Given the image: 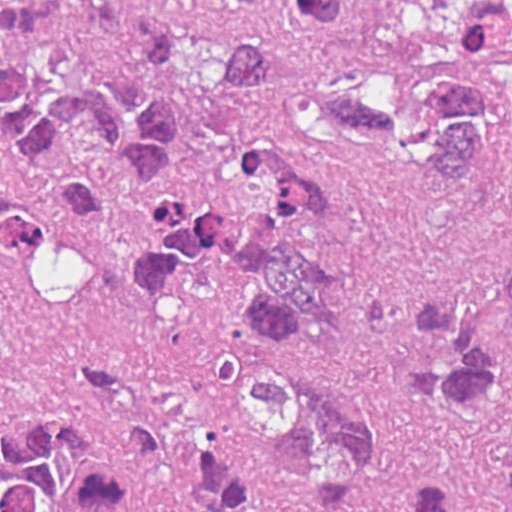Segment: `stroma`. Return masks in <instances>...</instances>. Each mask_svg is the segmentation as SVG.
Masks as SVG:
<instances>
[{
    "instance_id": "stroma-1",
    "label": "stroma",
    "mask_w": 512,
    "mask_h": 512,
    "mask_svg": "<svg viewBox=\"0 0 512 512\" xmlns=\"http://www.w3.org/2000/svg\"><path fill=\"white\" fill-rule=\"evenodd\" d=\"M191 19L239 25L274 49L258 111L262 129L302 142L345 170L353 189L345 364L386 419L382 476L357 509L403 512L418 473L446 448L438 426L401 384L395 359L415 304L434 286L488 259L501 222L404 163H363L313 130L301 88L323 76L364 80L357 46L296 25L285 0H149ZM482 0H355L367 29L387 41H435ZM109 206L98 222L63 208L40 176L0 143L43 207L55 236L84 249L95 300L74 312L41 298L29 272L41 250L0 258V444L74 424L69 443L119 470L100 512H201L187 501V461L207 424L223 343L252 313L235 277L199 287L162 309L124 293L120 270L152 218L146 178L128 175L101 149ZM51 236V237H52Z\"/></svg>"
}]
</instances>
